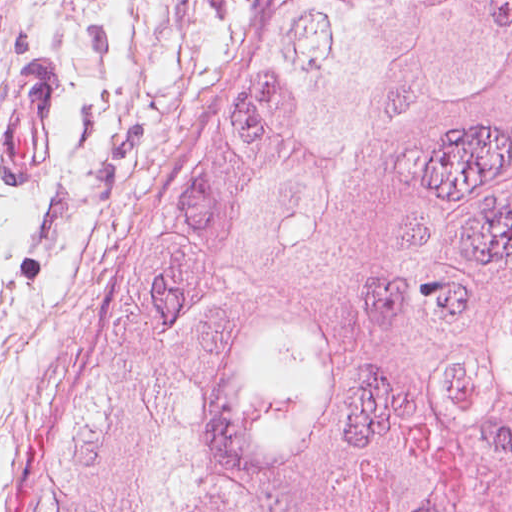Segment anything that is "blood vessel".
Segmentation results:
<instances>
[{
	"instance_id": "8fb6f2fc",
	"label": "blood vessel",
	"mask_w": 512,
	"mask_h": 512,
	"mask_svg": "<svg viewBox=\"0 0 512 512\" xmlns=\"http://www.w3.org/2000/svg\"><path fill=\"white\" fill-rule=\"evenodd\" d=\"M36 60L0 102V175L8 188H39L59 174V66Z\"/></svg>"
}]
</instances>
